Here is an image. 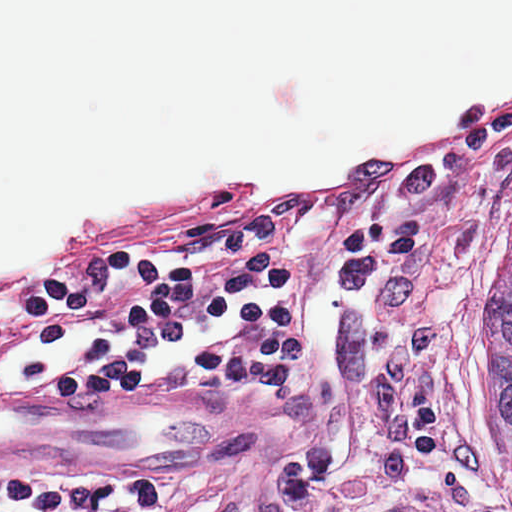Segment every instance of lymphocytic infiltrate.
Wrapping results in <instances>:
<instances>
[{
    "mask_svg": "<svg viewBox=\"0 0 512 512\" xmlns=\"http://www.w3.org/2000/svg\"><path fill=\"white\" fill-rule=\"evenodd\" d=\"M146 280L153 312L145 327L111 353L50 372L53 389L138 393L180 353L213 339L230 307L268 285L237 213L209 233L92 228L61 244L38 269L0 279V346L35 341L87 307L136 292Z\"/></svg>",
    "mask_w": 512,
    "mask_h": 512,
    "instance_id": "lymphocytic-infiltrate-1",
    "label": "lymphocytic infiltrate"
}]
</instances>
